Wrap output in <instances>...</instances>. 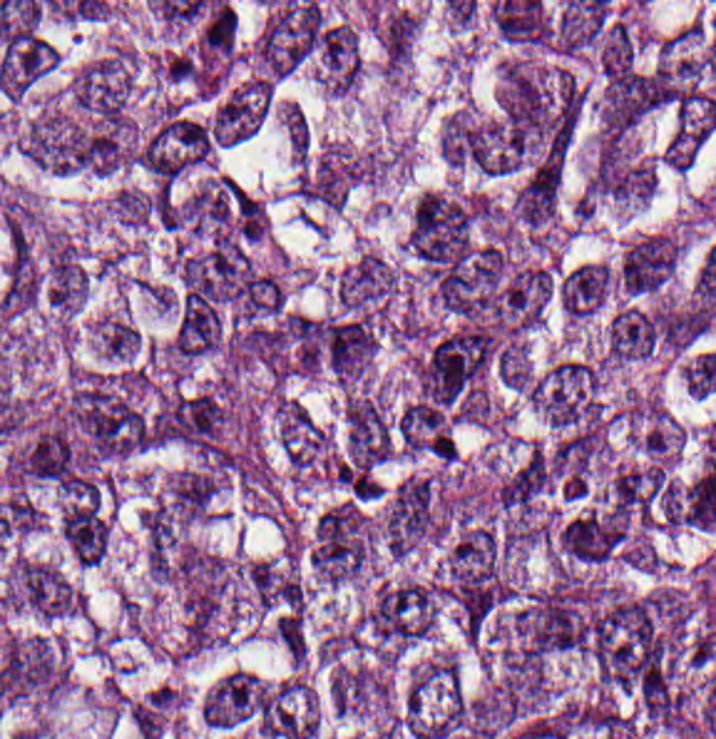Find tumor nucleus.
Instances as JSON below:
<instances>
[{
    "mask_svg": "<svg viewBox=\"0 0 716 739\" xmlns=\"http://www.w3.org/2000/svg\"><path fill=\"white\" fill-rule=\"evenodd\" d=\"M176 588L181 649L194 652L229 619L240 592L241 571L219 551L185 541Z\"/></svg>",
    "mask_w": 716,
    "mask_h": 739,
    "instance_id": "1",
    "label": "tumor nucleus"
},
{
    "mask_svg": "<svg viewBox=\"0 0 716 739\" xmlns=\"http://www.w3.org/2000/svg\"><path fill=\"white\" fill-rule=\"evenodd\" d=\"M532 404L554 434L596 442L605 408L597 357L569 355L534 377Z\"/></svg>",
    "mask_w": 716,
    "mask_h": 739,
    "instance_id": "2",
    "label": "tumor nucleus"
},
{
    "mask_svg": "<svg viewBox=\"0 0 716 739\" xmlns=\"http://www.w3.org/2000/svg\"><path fill=\"white\" fill-rule=\"evenodd\" d=\"M376 553V521L356 496H342L315 518L305 542L310 572L320 581L338 586L360 575Z\"/></svg>",
    "mask_w": 716,
    "mask_h": 739,
    "instance_id": "3",
    "label": "tumor nucleus"
},
{
    "mask_svg": "<svg viewBox=\"0 0 716 739\" xmlns=\"http://www.w3.org/2000/svg\"><path fill=\"white\" fill-rule=\"evenodd\" d=\"M438 611V586L421 576L377 579L360 620V639L377 652L398 654L421 642Z\"/></svg>",
    "mask_w": 716,
    "mask_h": 739,
    "instance_id": "4",
    "label": "tumor nucleus"
},
{
    "mask_svg": "<svg viewBox=\"0 0 716 739\" xmlns=\"http://www.w3.org/2000/svg\"><path fill=\"white\" fill-rule=\"evenodd\" d=\"M378 153L338 140L305 145L293 182L295 204L308 216L336 206L376 174Z\"/></svg>",
    "mask_w": 716,
    "mask_h": 739,
    "instance_id": "5",
    "label": "tumor nucleus"
},
{
    "mask_svg": "<svg viewBox=\"0 0 716 739\" xmlns=\"http://www.w3.org/2000/svg\"><path fill=\"white\" fill-rule=\"evenodd\" d=\"M6 609L46 618L69 619L84 614V591L52 561L15 555L2 585Z\"/></svg>",
    "mask_w": 716,
    "mask_h": 739,
    "instance_id": "6",
    "label": "tumor nucleus"
},
{
    "mask_svg": "<svg viewBox=\"0 0 716 739\" xmlns=\"http://www.w3.org/2000/svg\"><path fill=\"white\" fill-rule=\"evenodd\" d=\"M658 99L657 85L645 61L604 53L596 91L599 134H625Z\"/></svg>",
    "mask_w": 716,
    "mask_h": 739,
    "instance_id": "7",
    "label": "tumor nucleus"
},
{
    "mask_svg": "<svg viewBox=\"0 0 716 739\" xmlns=\"http://www.w3.org/2000/svg\"><path fill=\"white\" fill-rule=\"evenodd\" d=\"M221 478L196 463L181 467L146 508L153 542H174L210 513Z\"/></svg>",
    "mask_w": 716,
    "mask_h": 739,
    "instance_id": "8",
    "label": "tumor nucleus"
},
{
    "mask_svg": "<svg viewBox=\"0 0 716 739\" xmlns=\"http://www.w3.org/2000/svg\"><path fill=\"white\" fill-rule=\"evenodd\" d=\"M275 427L283 466L295 480H331L336 457L325 424L288 399L278 407Z\"/></svg>",
    "mask_w": 716,
    "mask_h": 739,
    "instance_id": "9",
    "label": "tumor nucleus"
},
{
    "mask_svg": "<svg viewBox=\"0 0 716 739\" xmlns=\"http://www.w3.org/2000/svg\"><path fill=\"white\" fill-rule=\"evenodd\" d=\"M332 303L382 325L396 294V272L381 252L362 250L327 280Z\"/></svg>",
    "mask_w": 716,
    "mask_h": 739,
    "instance_id": "10",
    "label": "tumor nucleus"
},
{
    "mask_svg": "<svg viewBox=\"0 0 716 739\" xmlns=\"http://www.w3.org/2000/svg\"><path fill=\"white\" fill-rule=\"evenodd\" d=\"M68 84L86 119L127 122L132 87L127 56H101Z\"/></svg>",
    "mask_w": 716,
    "mask_h": 739,
    "instance_id": "11",
    "label": "tumor nucleus"
},
{
    "mask_svg": "<svg viewBox=\"0 0 716 739\" xmlns=\"http://www.w3.org/2000/svg\"><path fill=\"white\" fill-rule=\"evenodd\" d=\"M677 249L672 238L644 231L621 247L614 286L635 295L655 293L672 273Z\"/></svg>",
    "mask_w": 716,
    "mask_h": 739,
    "instance_id": "12",
    "label": "tumor nucleus"
},
{
    "mask_svg": "<svg viewBox=\"0 0 716 739\" xmlns=\"http://www.w3.org/2000/svg\"><path fill=\"white\" fill-rule=\"evenodd\" d=\"M112 525L99 494H68L59 518V535L76 562L99 564Z\"/></svg>",
    "mask_w": 716,
    "mask_h": 739,
    "instance_id": "13",
    "label": "tumor nucleus"
},
{
    "mask_svg": "<svg viewBox=\"0 0 716 739\" xmlns=\"http://www.w3.org/2000/svg\"><path fill=\"white\" fill-rule=\"evenodd\" d=\"M556 285L565 312L571 318H585L609 298L612 271L607 265L579 260L561 272Z\"/></svg>",
    "mask_w": 716,
    "mask_h": 739,
    "instance_id": "14",
    "label": "tumor nucleus"
},
{
    "mask_svg": "<svg viewBox=\"0 0 716 739\" xmlns=\"http://www.w3.org/2000/svg\"><path fill=\"white\" fill-rule=\"evenodd\" d=\"M98 353L118 362L132 363L139 347V330L122 310H108L94 325Z\"/></svg>",
    "mask_w": 716,
    "mask_h": 739,
    "instance_id": "15",
    "label": "tumor nucleus"
}]
</instances>
